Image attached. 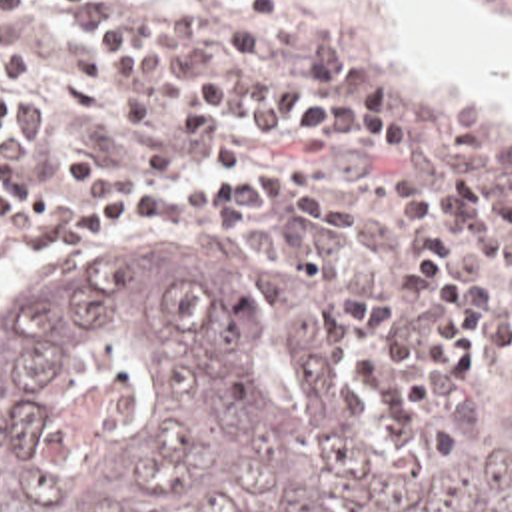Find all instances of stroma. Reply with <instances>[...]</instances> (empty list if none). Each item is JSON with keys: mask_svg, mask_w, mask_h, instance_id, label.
<instances>
[{"mask_svg": "<svg viewBox=\"0 0 512 512\" xmlns=\"http://www.w3.org/2000/svg\"><path fill=\"white\" fill-rule=\"evenodd\" d=\"M196 29L212 43V57L194 73L218 71L234 79H302L290 59L326 57L348 75H384L398 83L402 103L416 119V152L388 154L358 137H340L312 121H268L222 115L216 137L192 154L168 137L188 77L176 79V105L156 121L162 144L178 158L172 174L150 176L162 186H192L230 170L256 172V204L238 214H206L156 230L126 226L118 234L66 244L54 250L26 248L0 236V302L28 284L68 266L78 256L114 244L166 232H254L268 246V266L250 292L258 328L284 306H306L336 330L346 356L364 384L376 420V440L394 444L408 434L420 412H440L450 458L468 448L474 402L506 376V320L512 286H502L494 264L486 286H466L482 306V366L464 380H444L436 400L410 418H388L380 386L364 360L372 346L366 330L348 322L340 294L384 292L396 298V318L406 334H422L434 320V296L424 280L402 266L400 254L416 228L404 218L396 184L418 180L434 198L454 202L446 172L468 162L496 178H512V127L486 111L440 97L412 65L378 41V0H290L280 7L282 27L250 59L232 57L216 39L220 0H184ZM468 7H512V0H462ZM34 35L38 61L14 71L22 111L14 127V152L52 186H66V150L90 148L118 168H136L110 123L108 109L76 123L72 109V57L68 33L48 0H34L18 17L0 23V45ZM496 226H468L462 234Z\"/></svg>", "mask_w": 512, "mask_h": 512, "instance_id": "stroma-1", "label": "stroma"}]
</instances>
